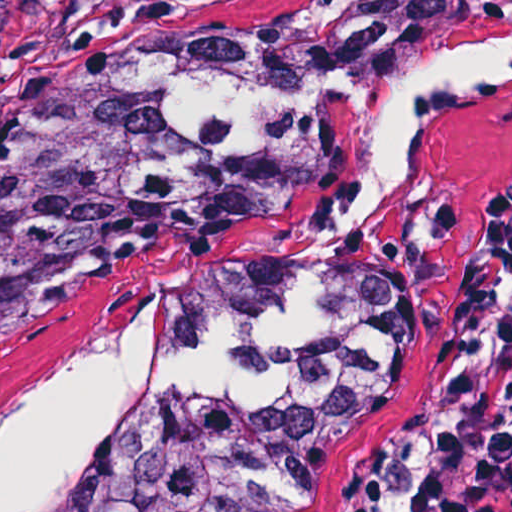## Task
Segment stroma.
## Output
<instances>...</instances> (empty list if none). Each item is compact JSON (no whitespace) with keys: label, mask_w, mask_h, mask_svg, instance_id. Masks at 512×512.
<instances>
[{"label":"stroma","mask_w":512,"mask_h":512,"mask_svg":"<svg viewBox=\"0 0 512 512\" xmlns=\"http://www.w3.org/2000/svg\"><path fill=\"white\" fill-rule=\"evenodd\" d=\"M436 0H11L0 113L45 96L117 47L205 27H286L315 12L406 13ZM404 83L372 95L322 186L270 223L155 231L0 318V430L111 328L163 320L249 263L281 250L357 256L386 272L403 309L406 378L364 485L336 512H413L422 478L465 412L454 313L487 211L512 184V80L436 101L387 206L339 231V208Z\"/></svg>","instance_id":"obj_1"}]
</instances>
